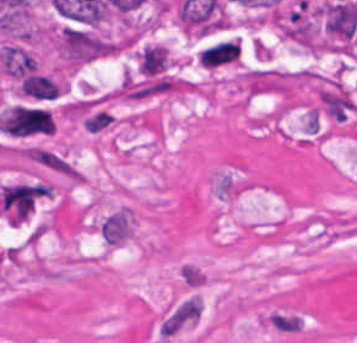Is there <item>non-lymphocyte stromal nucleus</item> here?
I'll return each mask as SVG.
<instances>
[{
	"mask_svg": "<svg viewBox=\"0 0 357 343\" xmlns=\"http://www.w3.org/2000/svg\"><path fill=\"white\" fill-rule=\"evenodd\" d=\"M20 96L34 101H51L63 90V85L47 74L33 73L17 80Z\"/></svg>",
	"mask_w": 357,
	"mask_h": 343,
	"instance_id": "3746e769",
	"label": "non-lymphocyte stromal nucleus"
},
{
	"mask_svg": "<svg viewBox=\"0 0 357 343\" xmlns=\"http://www.w3.org/2000/svg\"><path fill=\"white\" fill-rule=\"evenodd\" d=\"M34 163L71 184H80L79 169L57 151L36 146Z\"/></svg>",
	"mask_w": 357,
	"mask_h": 343,
	"instance_id": "fc2b8d12",
	"label": "non-lymphocyte stromal nucleus"
},
{
	"mask_svg": "<svg viewBox=\"0 0 357 343\" xmlns=\"http://www.w3.org/2000/svg\"><path fill=\"white\" fill-rule=\"evenodd\" d=\"M115 117L106 111H98L95 114L84 119V128L89 131H100L110 124Z\"/></svg>",
	"mask_w": 357,
	"mask_h": 343,
	"instance_id": "81446118",
	"label": "non-lymphocyte stromal nucleus"
},
{
	"mask_svg": "<svg viewBox=\"0 0 357 343\" xmlns=\"http://www.w3.org/2000/svg\"><path fill=\"white\" fill-rule=\"evenodd\" d=\"M53 120L46 108L13 105L3 111L2 131L14 135L52 133Z\"/></svg>",
	"mask_w": 357,
	"mask_h": 343,
	"instance_id": "a72fc3eb",
	"label": "non-lymphocyte stromal nucleus"
},
{
	"mask_svg": "<svg viewBox=\"0 0 357 343\" xmlns=\"http://www.w3.org/2000/svg\"><path fill=\"white\" fill-rule=\"evenodd\" d=\"M202 301L197 294H189L177 300L160 318L157 335L161 343H167L200 319Z\"/></svg>",
	"mask_w": 357,
	"mask_h": 343,
	"instance_id": "dd21d789",
	"label": "non-lymphocyte stromal nucleus"
}]
</instances>
